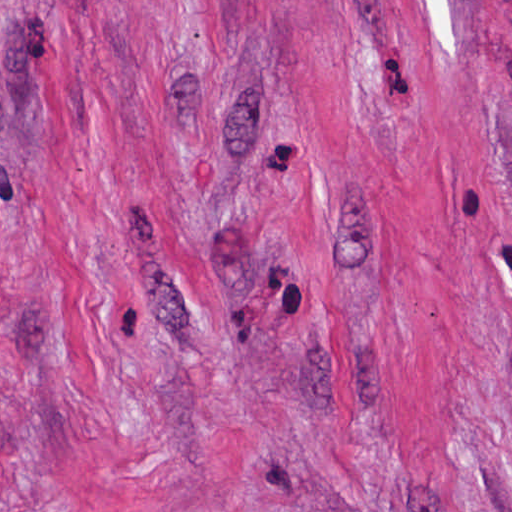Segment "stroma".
I'll return each mask as SVG.
<instances>
[{
  "label": "stroma",
  "mask_w": 512,
  "mask_h": 512,
  "mask_svg": "<svg viewBox=\"0 0 512 512\" xmlns=\"http://www.w3.org/2000/svg\"><path fill=\"white\" fill-rule=\"evenodd\" d=\"M0 512H512L503 0H0Z\"/></svg>",
  "instance_id": "35a3bbf8"
}]
</instances>
